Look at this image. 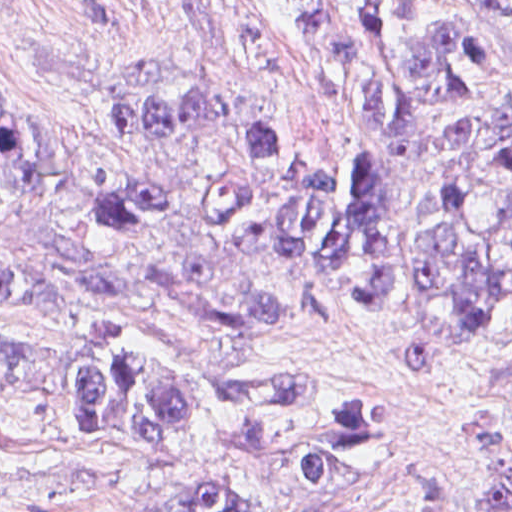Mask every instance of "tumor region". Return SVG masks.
<instances>
[{"instance_id": "tumor-region-1", "label": "tumor region", "mask_w": 512, "mask_h": 512, "mask_svg": "<svg viewBox=\"0 0 512 512\" xmlns=\"http://www.w3.org/2000/svg\"><path fill=\"white\" fill-rule=\"evenodd\" d=\"M225 1L242 46L290 72L250 1ZM258 1L376 145L316 150L209 85H125L68 109L0 81V311L145 306L192 338L180 355L108 325L70 351L0 340V389L66 394L84 437L143 463L181 456L199 403L212 443L239 453L312 418L280 459L305 485H340L383 456L382 411L367 392L287 390L264 354L282 317L269 275L315 271L471 333L512 329V132L471 115L512 67L463 0L466 18L443 0ZM132 512L256 509L204 482ZM347 512L435 504L416 490Z\"/></svg>"}]
</instances>
